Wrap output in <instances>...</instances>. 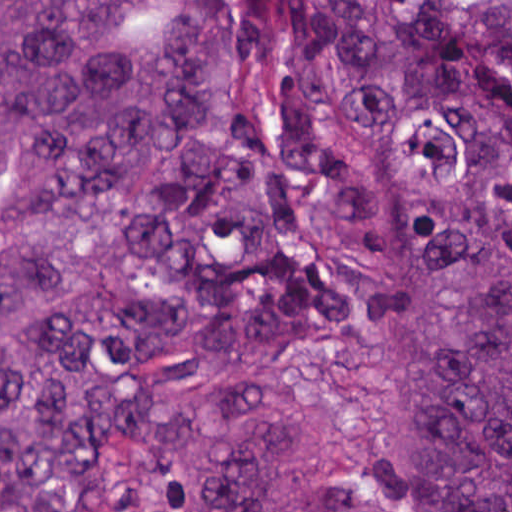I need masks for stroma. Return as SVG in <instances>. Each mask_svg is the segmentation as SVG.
<instances>
[{
	"label": "stroma",
	"mask_w": 512,
	"mask_h": 512,
	"mask_svg": "<svg viewBox=\"0 0 512 512\" xmlns=\"http://www.w3.org/2000/svg\"><path fill=\"white\" fill-rule=\"evenodd\" d=\"M200 193V167L182 219L164 242L161 285L169 304L196 331L199 375L149 432L129 447L89 512H152L178 480L217 388V343L187 290V250ZM360 301L352 320L284 339L287 357L307 383V414L283 443V480L294 512H384L401 435L387 398L352 375Z\"/></svg>",
	"instance_id": "stroma-1"
}]
</instances>
